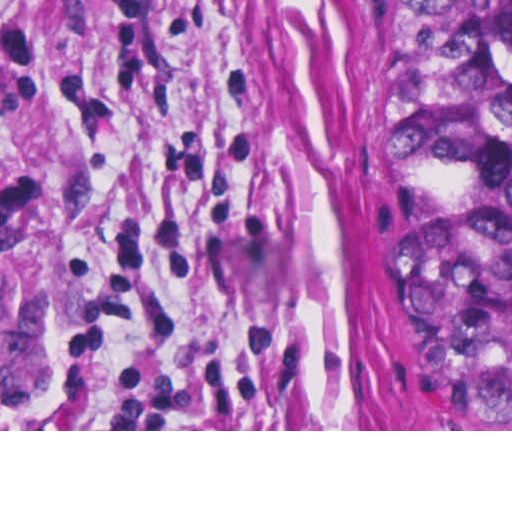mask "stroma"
I'll return each instance as SVG.
<instances>
[{"mask_svg":"<svg viewBox=\"0 0 512 512\" xmlns=\"http://www.w3.org/2000/svg\"><path fill=\"white\" fill-rule=\"evenodd\" d=\"M398 0H0V431L391 429Z\"/></svg>","mask_w":512,"mask_h":512,"instance_id":"obj_1","label":"stroma"}]
</instances>
